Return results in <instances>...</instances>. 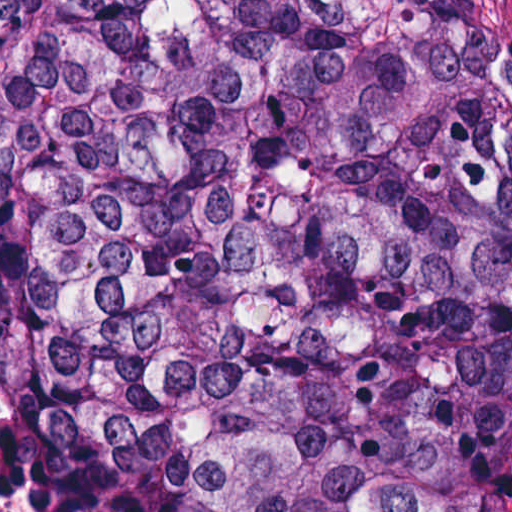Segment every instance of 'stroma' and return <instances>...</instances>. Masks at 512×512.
Here are the masks:
<instances>
[{
	"label": "stroma",
	"instance_id": "obj_1",
	"mask_svg": "<svg viewBox=\"0 0 512 512\" xmlns=\"http://www.w3.org/2000/svg\"><path fill=\"white\" fill-rule=\"evenodd\" d=\"M0 1H393L436 8L512 24V0H0ZM0 396L23 430L28 451V492L33 512H44L29 487V433L19 413L10 405L0 383Z\"/></svg>",
	"mask_w": 512,
	"mask_h": 512
}]
</instances>
